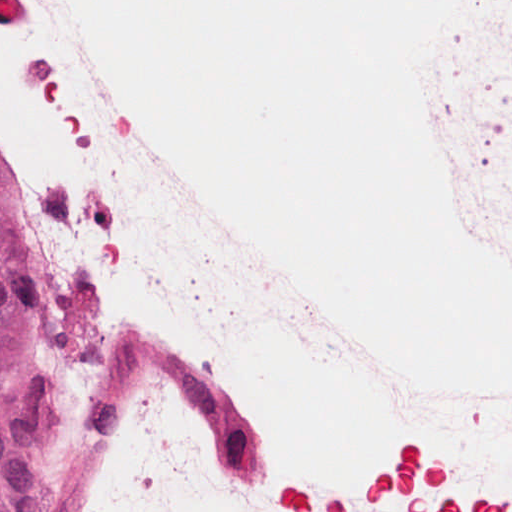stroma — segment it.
I'll return each instance as SVG.
<instances>
[{"instance_id": "1", "label": "stroma", "mask_w": 512, "mask_h": 512, "mask_svg": "<svg viewBox=\"0 0 512 512\" xmlns=\"http://www.w3.org/2000/svg\"><path fill=\"white\" fill-rule=\"evenodd\" d=\"M0 182L9 194L1 169ZM34 340L39 360L38 448L18 463H0V512H49L78 446L88 386L53 363L40 346L35 320Z\"/></svg>"}]
</instances>
